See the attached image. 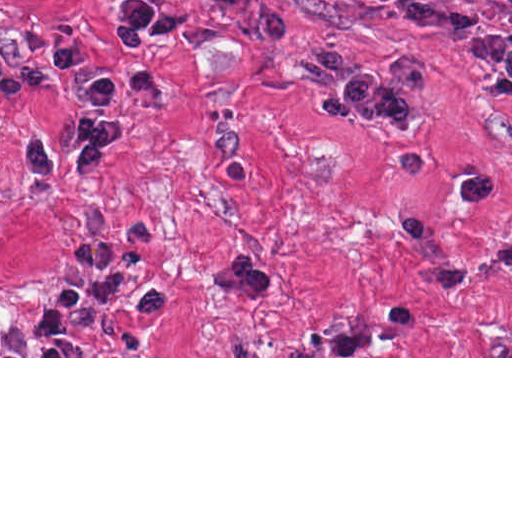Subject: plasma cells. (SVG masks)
Segmentation results:
<instances>
[{
	"label": "plasma cells",
	"instance_id": "obj_1",
	"mask_svg": "<svg viewBox=\"0 0 512 512\" xmlns=\"http://www.w3.org/2000/svg\"><path fill=\"white\" fill-rule=\"evenodd\" d=\"M500 1L512 6V0ZM296 75L313 91L331 89L315 105L318 114L329 123L373 119L396 134L418 129L416 97L437 86L436 74L411 60L398 63L392 79L380 70L363 72L336 44L308 60Z\"/></svg>",
	"mask_w": 512,
	"mask_h": 512
}]
</instances>
